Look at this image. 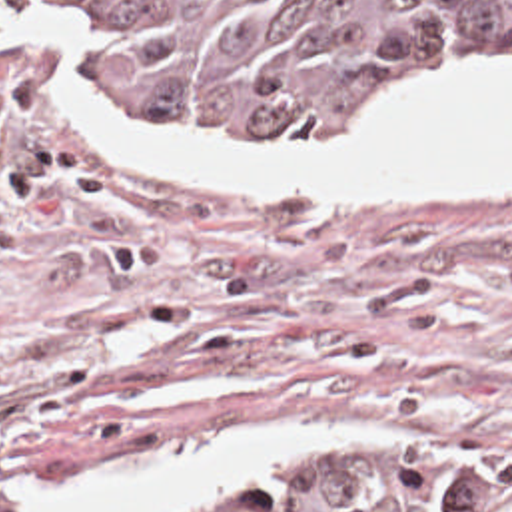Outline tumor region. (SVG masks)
<instances>
[{"instance_id":"1","label":"tumor region","mask_w":512,"mask_h":512,"mask_svg":"<svg viewBox=\"0 0 512 512\" xmlns=\"http://www.w3.org/2000/svg\"><path fill=\"white\" fill-rule=\"evenodd\" d=\"M446 61H512V0H0V141L115 105L330 139L378 81ZM121 512H512V490L438 454L330 446Z\"/></svg>"}]
</instances>
